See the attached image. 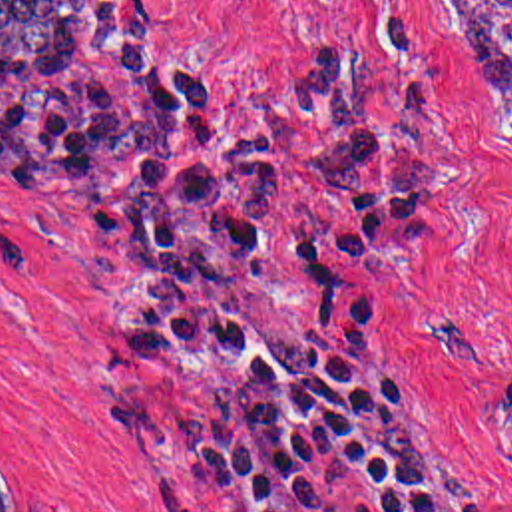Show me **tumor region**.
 Instances as JSON below:
<instances>
[{
    "mask_svg": "<svg viewBox=\"0 0 512 512\" xmlns=\"http://www.w3.org/2000/svg\"><path fill=\"white\" fill-rule=\"evenodd\" d=\"M448 3L512 135V0ZM0 91L53 107L125 167V240L143 272L127 368L229 364L185 418L111 406L109 438L201 487L258 471L286 428V374L256 348L237 290L272 248L286 167L217 103L197 57L127 39L99 0H0ZM0 512H45L14 495L2 464Z\"/></svg>",
    "mask_w": 512,
    "mask_h": 512,
    "instance_id": "tumor-region-1",
    "label": "tumor region"
}]
</instances>
